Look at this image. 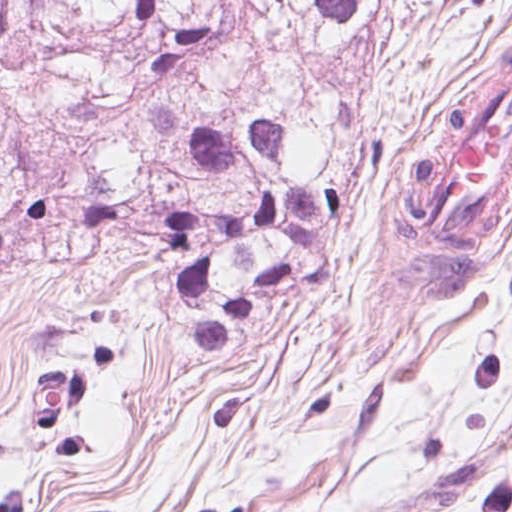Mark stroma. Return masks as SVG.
Instances as JSON below:
<instances>
[{
    "instance_id": "35a3bbf8",
    "label": "stroma",
    "mask_w": 512,
    "mask_h": 512,
    "mask_svg": "<svg viewBox=\"0 0 512 512\" xmlns=\"http://www.w3.org/2000/svg\"><path fill=\"white\" fill-rule=\"evenodd\" d=\"M512 42V0H367L332 62L360 157L320 282L236 356L192 348L161 259L42 268L0 290V512H512V236L403 342H359L385 172L417 107ZM510 103L460 183L493 188ZM486 237L497 195L483 201Z\"/></svg>"
}]
</instances>
